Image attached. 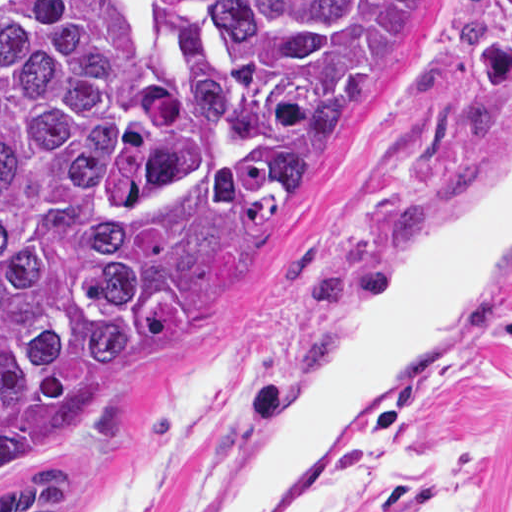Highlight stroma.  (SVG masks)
Returning a JSON list of instances; mask_svg holds the SVG:
<instances>
[{
  "instance_id": "obj_1",
  "label": "stroma",
  "mask_w": 512,
  "mask_h": 512,
  "mask_svg": "<svg viewBox=\"0 0 512 512\" xmlns=\"http://www.w3.org/2000/svg\"><path fill=\"white\" fill-rule=\"evenodd\" d=\"M512 135V0H435L317 184L265 226L317 250L329 295L222 303L162 346L137 414L94 442L86 512H191L340 363L369 261ZM511 442L482 512H512V275L469 349L356 423L278 512H423Z\"/></svg>"
}]
</instances>
